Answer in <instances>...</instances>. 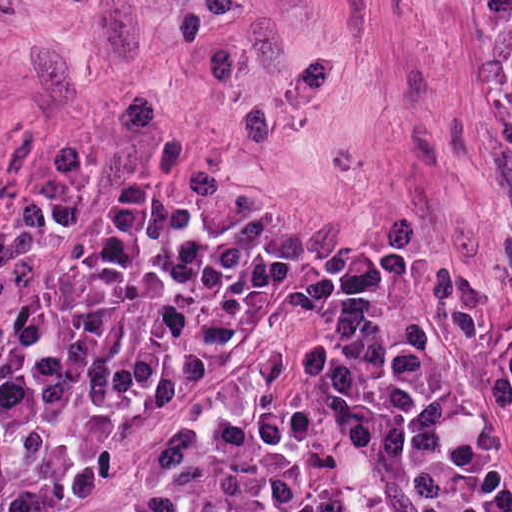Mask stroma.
Instances as JSON below:
<instances>
[{"mask_svg":"<svg viewBox=\"0 0 512 512\" xmlns=\"http://www.w3.org/2000/svg\"><path fill=\"white\" fill-rule=\"evenodd\" d=\"M478 1L0 0V246L146 190L438 271L512 328V133L467 125L500 116ZM164 445L256 452L357 512L255 311L36 512H98Z\"/></svg>","mask_w":512,"mask_h":512,"instance_id":"1","label":"stroma"}]
</instances>
